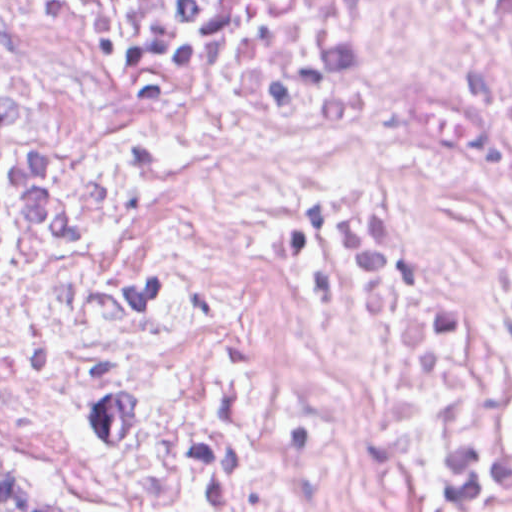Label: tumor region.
<instances>
[{
    "mask_svg": "<svg viewBox=\"0 0 512 512\" xmlns=\"http://www.w3.org/2000/svg\"><path fill=\"white\" fill-rule=\"evenodd\" d=\"M0 512H109L59 493L35 476L0 469Z\"/></svg>",
    "mask_w": 512,
    "mask_h": 512,
    "instance_id": "tumor-region-1",
    "label": "tumor region"
}]
</instances>
